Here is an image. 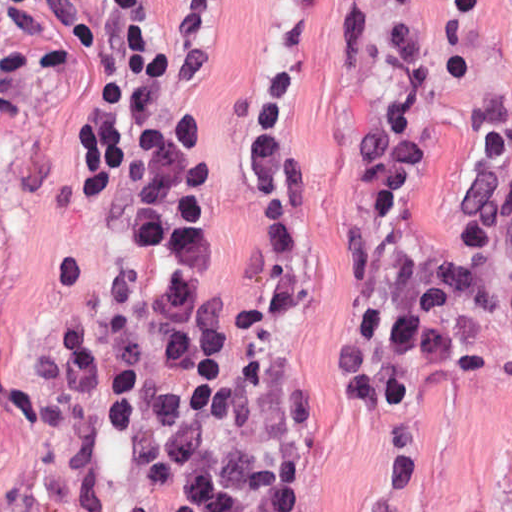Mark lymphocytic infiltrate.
<instances>
[{
	"instance_id": "1",
	"label": "lymphocytic infiltrate",
	"mask_w": 512,
	"mask_h": 512,
	"mask_svg": "<svg viewBox=\"0 0 512 512\" xmlns=\"http://www.w3.org/2000/svg\"><path fill=\"white\" fill-rule=\"evenodd\" d=\"M75 37L88 0H16L6 13ZM104 63L78 131L88 196L129 176L128 243L107 315L63 359L101 390L98 421L152 463L132 512H320L307 395L273 344L228 327L208 268L213 185L164 120L168 63L140 0H100Z\"/></svg>"
}]
</instances>
